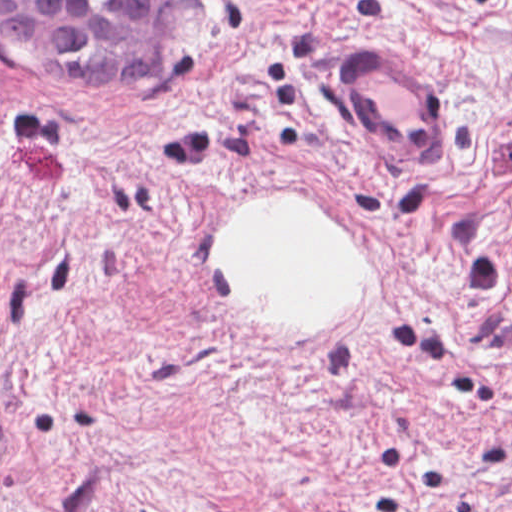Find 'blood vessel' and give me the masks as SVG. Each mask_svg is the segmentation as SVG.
Segmentation results:
<instances>
[{"mask_svg":"<svg viewBox=\"0 0 512 512\" xmlns=\"http://www.w3.org/2000/svg\"><path fill=\"white\" fill-rule=\"evenodd\" d=\"M355 43L342 51L339 101L353 138L394 167L436 165L441 104L410 61L380 44ZM5 430L0 424V454Z\"/></svg>","mask_w":512,"mask_h":512,"instance_id":"obj_1","label":"blood vessel"}]
</instances>
